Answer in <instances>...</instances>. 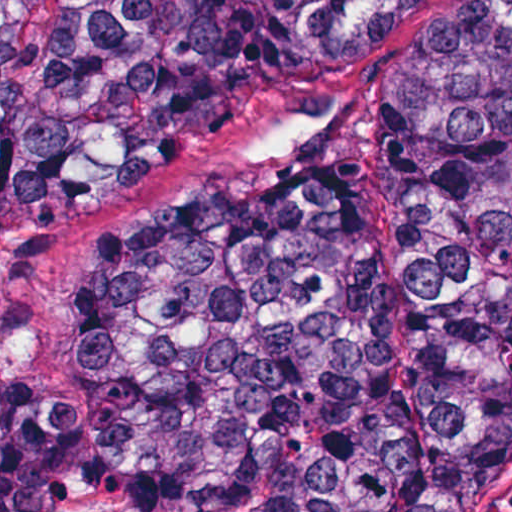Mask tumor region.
Wrapping results in <instances>:
<instances>
[{"label": "tumor region", "instance_id": "1", "mask_svg": "<svg viewBox=\"0 0 512 512\" xmlns=\"http://www.w3.org/2000/svg\"><path fill=\"white\" fill-rule=\"evenodd\" d=\"M445 0H0V244ZM284 151L85 245L60 386L0 379V512H498L512 494V0L394 71L383 177Z\"/></svg>", "mask_w": 512, "mask_h": 512}]
</instances>
